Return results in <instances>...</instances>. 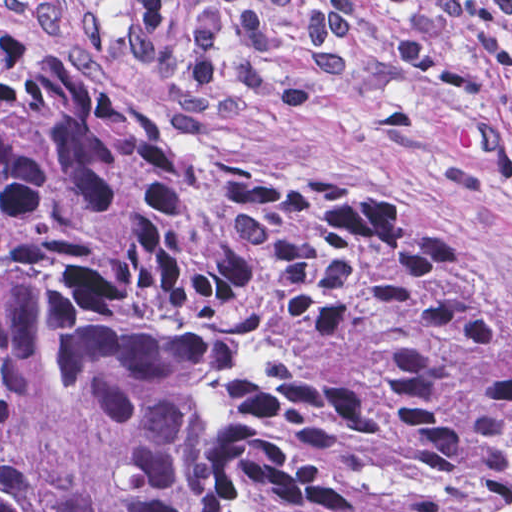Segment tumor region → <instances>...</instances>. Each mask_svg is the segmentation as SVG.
I'll return each mask as SVG.
<instances>
[{
	"label": "tumor region",
	"mask_w": 512,
	"mask_h": 512,
	"mask_svg": "<svg viewBox=\"0 0 512 512\" xmlns=\"http://www.w3.org/2000/svg\"><path fill=\"white\" fill-rule=\"evenodd\" d=\"M0 512H512V326L400 198L0 10Z\"/></svg>",
	"instance_id": "1"
}]
</instances>
